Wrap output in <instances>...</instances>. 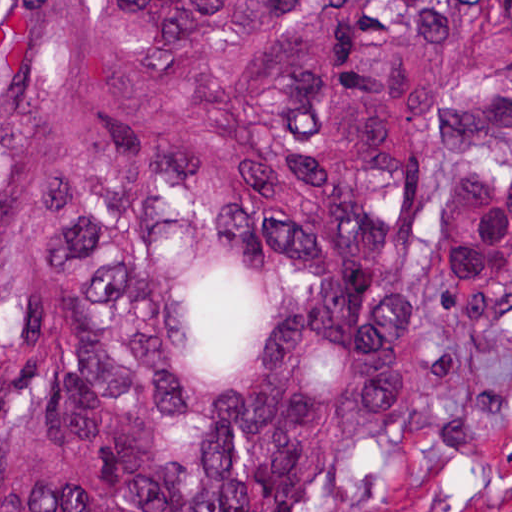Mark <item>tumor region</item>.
<instances>
[{
    "label": "tumor region",
    "instance_id": "tumor-region-1",
    "mask_svg": "<svg viewBox=\"0 0 512 512\" xmlns=\"http://www.w3.org/2000/svg\"><path fill=\"white\" fill-rule=\"evenodd\" d=\"M0 512H512V0H0Z\"/></svg>",
    "mask_w": 512,
    "mask_h": 512
}]
</instances>
